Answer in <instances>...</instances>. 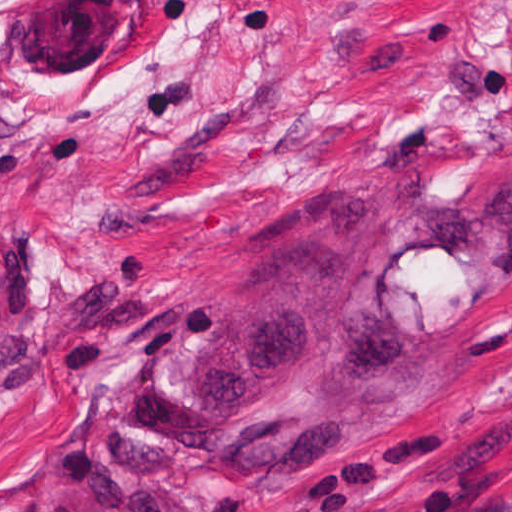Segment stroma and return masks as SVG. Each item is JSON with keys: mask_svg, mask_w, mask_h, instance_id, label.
Returning <instances> with one entry per match:
<instances>
[{"mask_svg": "<svg viewBox=\"0 0 512 512\" xmlns=\"http://www.w3.org/2000/svg\"><path fill=\"white\" fill-rule=\"evenodd\" d=\"M332 181L480 232L512 187L509 0H0V512H90L47 474L88 387ZM164 480L201 512H512V288L429 415L309 474Z\"/></svg>", "mask_w": 512, "mask_h": 512, "instance_id": "obj_1", "label": "stroma"}]
</instances>
